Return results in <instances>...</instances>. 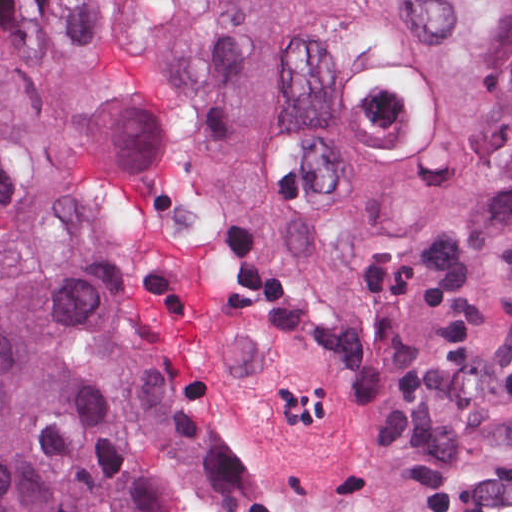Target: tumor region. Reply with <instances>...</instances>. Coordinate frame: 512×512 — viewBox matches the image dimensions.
<instances>
[{
  "mask_svg": "<svg viewBox=\"0 0 512 512\" xmlns=\"http://www.w3.org/2000/svg\"><path fill=\"white\" fill-rule=\"evenodd\" d=\"M47 2L0 1V512H200L187 383L217 512L512 470V0Z\"/></svg>",
  "mask_w": 512,
  "mask_h": 512,
  "instance_id": "obj_1",
  "label": "tumor region"
}]
</instances>
